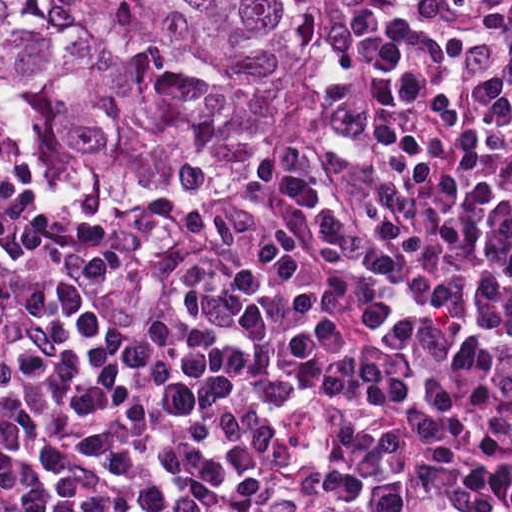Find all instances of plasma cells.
Listing matches in <instances>:
<instances>
[{"label": "plasma cells", "instance_id": "plasma-cells-1", "mask_svg": "<svg viewBox=\"0 0 512 512\" xmlns=\"http://www.w3.org/2000/svg\"><path fill=\"white\" fill-rule=\"evenodd\" d=\"M0 512H512V0H353L229 216L0 176Z\"/></svg>", "mask_w": 512, "mask_h": 512}]
</instances>
